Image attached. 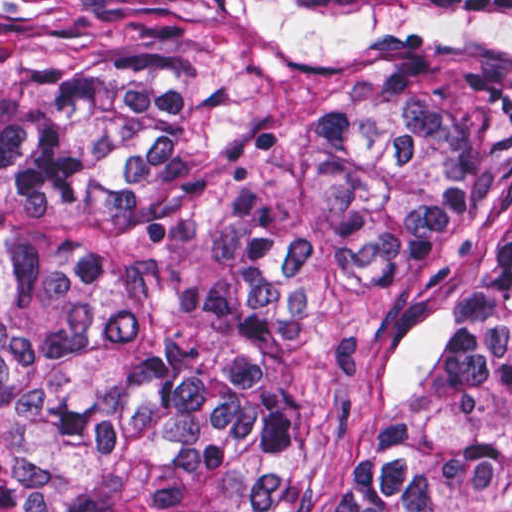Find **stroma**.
Returning a JSON list of instances; mask_svg holds the SVG:
<instances>
[{
    "label": "stroma",
    "instance_id": "obj_1",
    "mask_svg": "<svg viewBox=\"0 0 512 512\" xmlns=\"http://www.w3.org/2000/svg\"><path fill=\"white\" fill-rule=\"evenodd\" d=\"M446 512H512V490L492 505H452Z\"/></svg>",
    "mask_w": 512,
    "mask_h": 512
}]
</instances>
